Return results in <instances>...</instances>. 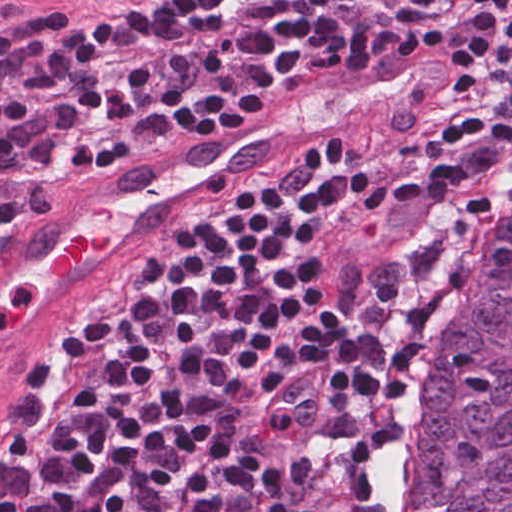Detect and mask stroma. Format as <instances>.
<instances>
[{
  "label": "stroma",
  "instance_id": "1",
  "mask_svg": "<svg viewBox=\"0 0 512 512\" xmlns=\"http://www.w3.org/2000/svg\"><path fill=\"white\" fill-rule=\"evenodd\" d=\"M167 1L0 0V20H37L69 9H152ZM326 74L290 71L254 120ZM500 105L490 94L485 66L471 46L462 67L443 89L420 100L397 120L346 134L345 170H363L373 176L390 178L438 167L493 125ZM230 132L217 131L195 141L155 147L137 154L94 180L83 198L206 151ZM301 148L254 167L218 172L194 185L120 237L1 374L0 431L26 377L28 364L38 343L55 321L87 297L119 289L137 263L169 240L181 216L232 198L255 172L288 165ZM44 217L41 216V220ZM25 230L15 238L14 243ZM282 427L294 446L343 455L361 461L372 469L378 488L379 512H386V483L398 437L361 419L356 411L292 421ZM0 471L12 481L15 480L11 460Z\"/></svg>",
  "mask_w": 512,
  "mask_h": 512
}]
</instances>
